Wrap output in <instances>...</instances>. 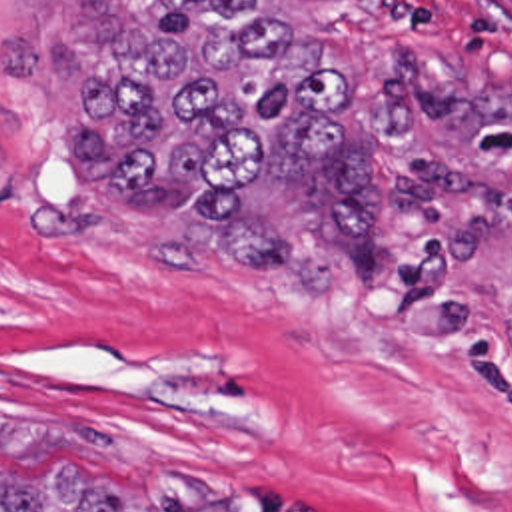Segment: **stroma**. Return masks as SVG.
Masks as SVG:
<instances>
[{"instance_id": "1", "label": "stroma", "mask_w": 512, "mask_h": 512, "mask_svg": "<svg viewBox=\"0 0 512 512\" xmlns=\"http://www.w3.org/2000/svg\"><path fill=\"white\" fill-rule=\"evenodd\" d=\"M322 36L452 88L512 84V0H346ZM94 0H0V419L102 437L0 445L140 512H512V114L474 142L490 234L414 252L392 302L300 294L198 252L178 214L72 162Z\"/></svg>"}]
</instances>
